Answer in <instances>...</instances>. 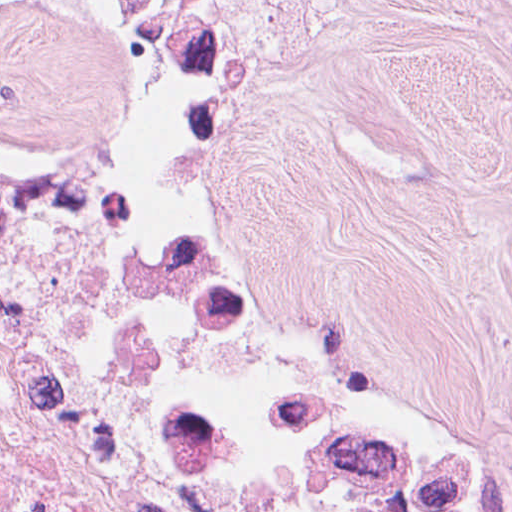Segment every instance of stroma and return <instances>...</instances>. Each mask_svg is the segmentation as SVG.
Instances as JSON below:
<instances>
[{
	"label": "stroma",
	"instance_id": "stroma-1",
	"mask_svg": "<svg viewBox=\"0 0 512 512\" xmlns=\"http://www.w3.org/2000/svg\"><path fill=\"white\" fill-rule=\"evenodd\" d=\"M119 99L361 356L512 452V0H0V116Z\"/></svg>",
	"mask_w": 512,
	"mask_h": 512
}]
</instances>
